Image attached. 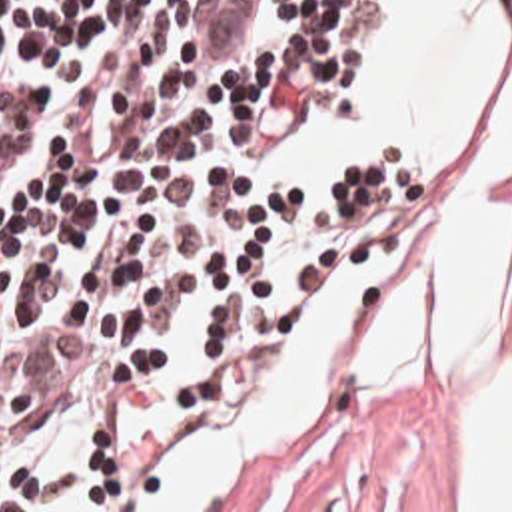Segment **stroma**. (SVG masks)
<instances>
[{
  "instance_id": "1",
  "label": "stroma",
  "mask_w": 512,
  "mask_h": 512,
  "mask_svg": "<svg viewBox=\"0 0 512 512\" xmlns=\"http://www.w3.org/2000/svg\"><path fill=\"white\" fill-rule=\"evenodd\" d=\"M402 231L392 247L394 273L368 299L358 345L374 355V333L396 269L416 237L418 185L404 173ZM512 207V179L506 185ZM460 393H392L378 407H334L282 457L245 512H460ZM265 409V407H263ZM217 447L149 509L215 465L263 413Z\"/></svg>"
}]
</instances>
